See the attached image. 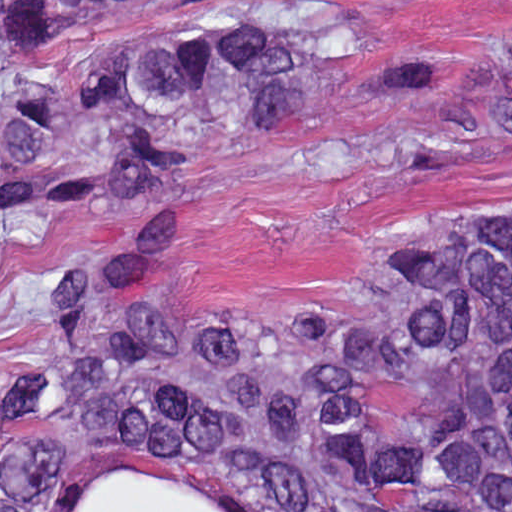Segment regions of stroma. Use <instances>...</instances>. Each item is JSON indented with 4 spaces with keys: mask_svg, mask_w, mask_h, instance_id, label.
I'll return each instance as SVG.
<instances>
[{
    "mask_svg": "<svg viewBox=\"0 0 512 512\" xmlns=\"http://www.w3.org/2000/svg\"><path fill=\"white\" fill-rule=\"evenodd\" d=\"M265 13L328 14L356 56L335 68L328 115L240 133L183 168L177 221L186 242L159 308L168 328H200L258 310L275 317L357 312L373 271L415 235L502 200L512 184V141L453 144L445 125L449 109L481 86V69L512 92V0L138 9L50 41L28 54L23 68L51 90L69 92L88 78L92 53L105 43ZM116 216L170 214L144 185L110 178L32 236L1 244L0 0V512L1 421L10 390L44 339L66 261ZM126 467L155 469L234 512H277L250 477L65 428L56 512H79L92 478ZM427 507L512 512V500L398 495L382 482L367 512Z\"/></svg>",
    "mask_w": 512,
    "mask_h": 512,
    "instance_id": "35a3bbf8",
    "label": "stroma"
}]
</instances>
